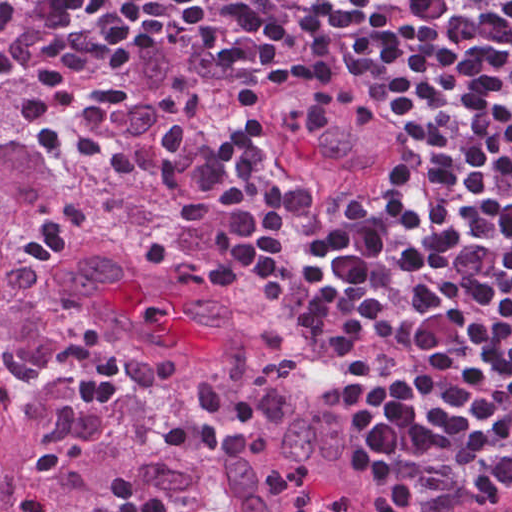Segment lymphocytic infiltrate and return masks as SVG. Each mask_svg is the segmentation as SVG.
Segmentation results:
<instances>
[{
    "label": "lymphocytic infiltrate",
    "instance_id": "lymphocytic-infiltrate-1",
    "mask_svg": "<svg viewBox=\"0 0 512 512\" xmlns=\"http://www.w3.org/2000/svg\"><path fill=\"white\" fill-rule=\"evenodd\" d=\"M54 1L71 29L27 111L90 175L119 142L110 83L135 45L183 32L207 46L203 190L283 327L362 361L337 404L384 483L512 489V0ZM326 56L371 71L399 124L393 169L346 205L249 128L285 69ZM160 441L253 450L250 434L179 417ZM100 507L215 512L122 471ZM17 512L61 511L33 488Z\"/></svg>",
    "mask_w": 512,
    "mask_h": 512
}]
</instances>
